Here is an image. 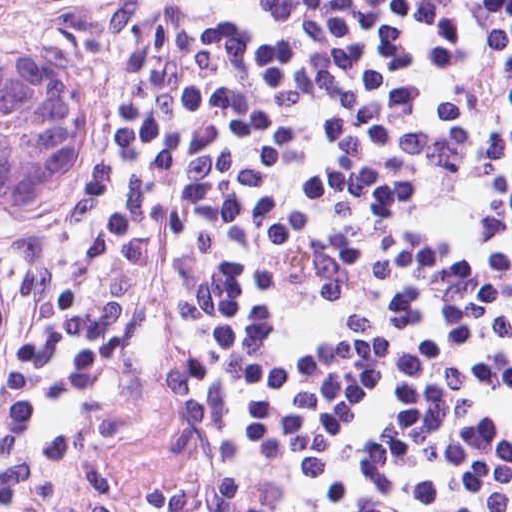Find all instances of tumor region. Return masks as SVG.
Listing matches in <instances>:
<instances>
[{
	"label": "tumor region",
	"instance_id": "obj_1",
	"mask_svg": "<svg viewBox=\"0 0 512 512\" xmlns=\"http://www.w3.org/2000/svg\"><path fill=\"white\" fill-rule=\"evenodd\" d=\"M124 147L125 115L113 96L0 39V229L109 174ZM7 326L0 272V367Z\"/></svg>",
	"mask_w": 512,
	"mask_h": 512
}]
</instances>
